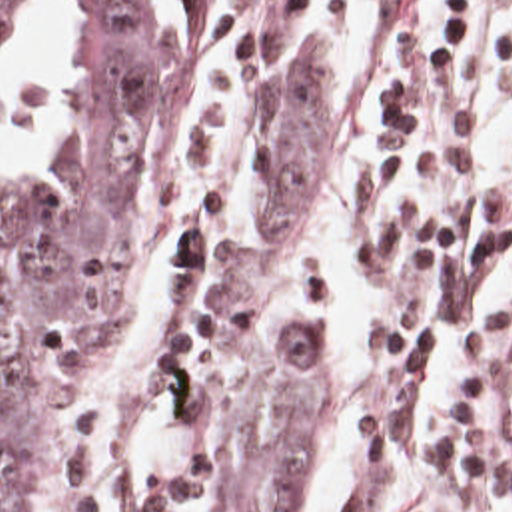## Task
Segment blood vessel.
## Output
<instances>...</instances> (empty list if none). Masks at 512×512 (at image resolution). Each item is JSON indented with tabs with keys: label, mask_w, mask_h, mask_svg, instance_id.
<instances>
[{
	"label": "blood vessel",
	"mask_w": 512,
	"mask_h": 512,
	"mask_svg": "<svg viewBox=\"0 0 512 512\" xmlns=\"http://www.w3.org/2000/svg\"><path fill=\"white\" fill-rule=\"evenodd\" d=\"M495 421L501 441L512 453V344L503 358L495 389Z\"/></svg>",
	"instance_id": "1"
}]
</instances>
